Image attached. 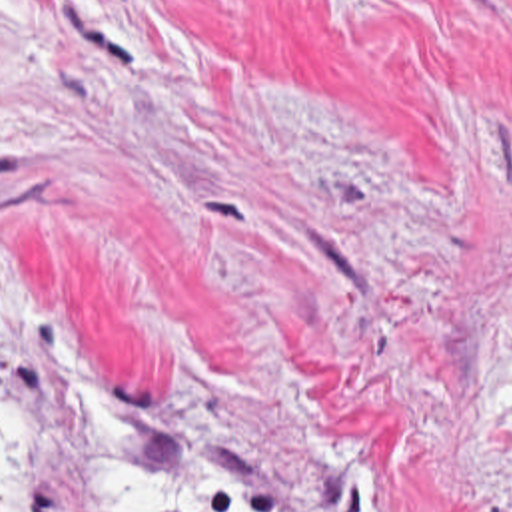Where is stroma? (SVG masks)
<instances>
[{
	"mask_svg": "<svg viewBox=\"0 0 512 512\" xmlns=\"http://www.w3.org/2000/svg\"><path fill=\"white\" fill-rule=\"evenodd\" d=\"M4 254L157 472L211 400L251 512H512V0H0ZM16 402L94 512L66 378Z\"/></svg>",
	"mask_w": 512,
	"mask_h": 512,
	"instance_id": "obj_1",
	"label": "stroma"
}]
</instances>
